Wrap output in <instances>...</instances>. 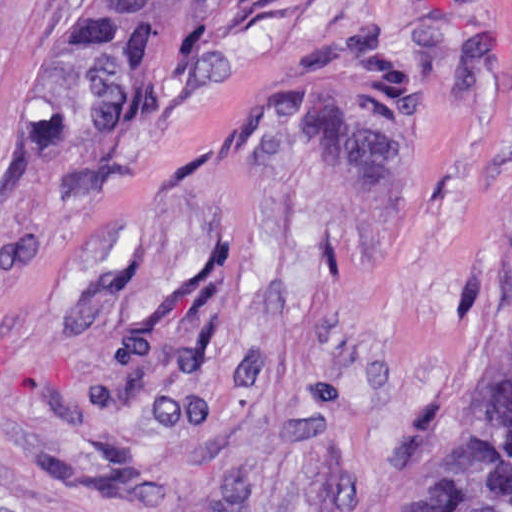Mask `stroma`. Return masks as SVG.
<instances>
[{"label":"stroma","mask_w":512,"mask_h":512,"mask_svg":"<svg viewBox=\"0 0 512 512\" xmlns=\"http://www.w3.org/2000/svg\"><path fill=\"white\" fill-rule=\"evenodd\" d=\"M79 0H0V512H352L512 360V0H283L129 132L43 139Z\"/></svg>","instance_id":"stroma-1"}]
</instances>
